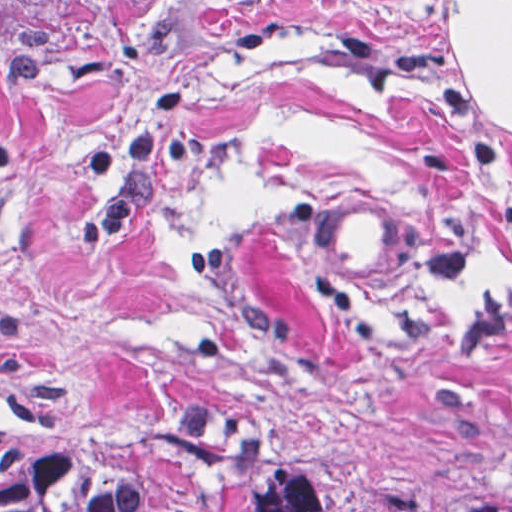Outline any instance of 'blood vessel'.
Wrapping results in <instances>:
<instances>
[{
  "mask_svg": "<svg viewBox=\"0 0 512 512\" xmlns=\"http://www.w3.org/2000/svg\"><path fill=\"white\" fill-rule=\"evenodd\" d=\"M305 219L310 241L346 274L380 290L409 286L413 230L369 196L315 191Z\"/></svg>",
  "mask_w": 512,
  "mask_h": 512,
  "instance_id": "1",
  "label": "blood vessel"
}]
</instances>
